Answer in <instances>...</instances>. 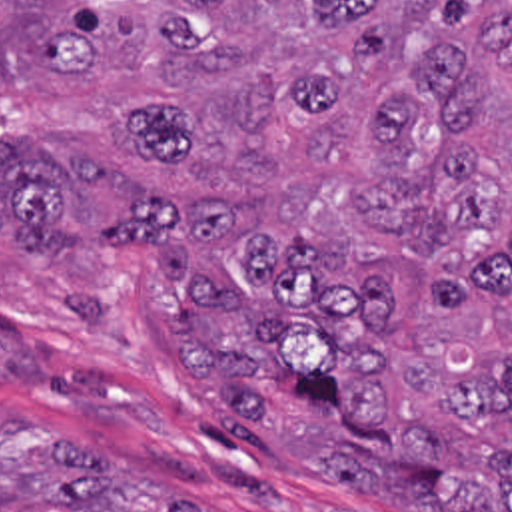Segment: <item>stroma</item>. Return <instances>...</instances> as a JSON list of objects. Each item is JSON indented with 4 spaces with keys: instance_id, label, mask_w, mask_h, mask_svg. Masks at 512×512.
<instances>
[{
    "instance_id": "35a3bbf8",
    "label": "stroma",
    "mask_w": 512,
    "mask_h": 512,
    "mask_svg": "<svg viewBox=\"0 0 512 512\" xmlns=\"http://www.w3.org/2000/svg\"><path fill=\"white\" fill-rule=\"evenodd\" d=\"M176 289L143 251H0V418L93 452L115 478L208 512H390L230 432L162 341Z\"/></svg>"
}]
</instances>
